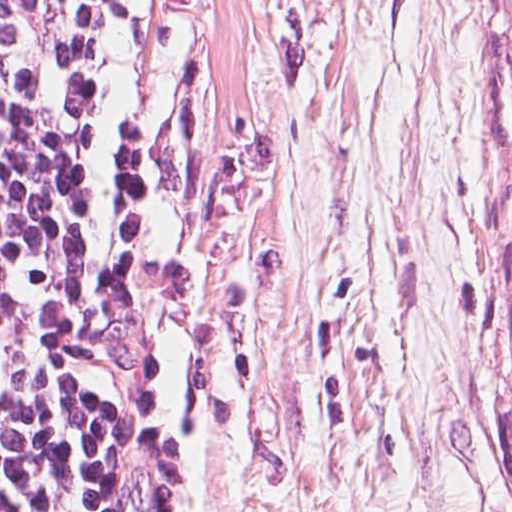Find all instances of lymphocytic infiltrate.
<instances>
[{"mask_svg":"<svg viewBox=\"0 0 512 512\" xmlns=\"http://www.w3.org/2000/svg\"><path fill=\"white\" fill-rule=\"evenodd\" d=\"M58 0H0V512H145L129 410L169 204L131 150L50 207Z\"/></svg>","mask_w":512,"mask_h":512,"instance_id":"lymphocytic-infiltrate-1","label":"lymphocytic infiltrate"}]
</instances>
